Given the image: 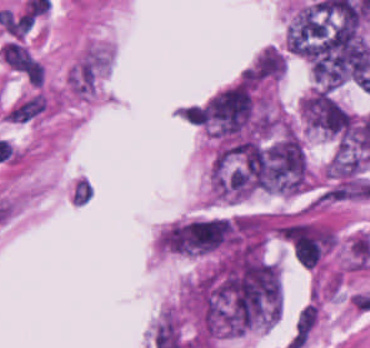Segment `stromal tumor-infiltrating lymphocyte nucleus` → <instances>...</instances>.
I'll return each instance as SVG.
<instances>
[{
    "instance_id": "1",
    "label": "stromal tumor-infiltrating lymphocyte nucleus",
    "mask_w": 370,
    "mask_h": 348,
    "mask_svg": "<svg viewBox=\"0 0 370 348\" xmlns=\"http://www.w3.org/2000/svg\"><path fill=\"white\" fill-rule=\"evenodd\" d=\"M317 315L318 303L314 302L305 307L295 322L296 332L306 338L317 320Z\"/></svg>"
}]
</instances>
